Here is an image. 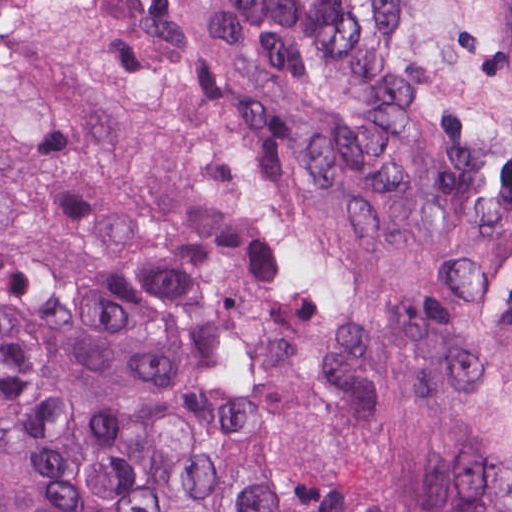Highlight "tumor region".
I'll list each match as a JSON object with an SVG mask.
<instances>
[{
    "instance_id": "obj_1",
    "label": "tumor region",
    "mask_w": 512,
    "mask_h": 512,
    "mask_svg": "<svg viewBox=\"0 0 512 512\" xmlns=\"http://www.w3.org/2000/svg\"><path fill=\"white\" fill-rule=\"evenodd\" d=\"M0 512H512V0H0Z\"/></svg>"
}]
</instances>
